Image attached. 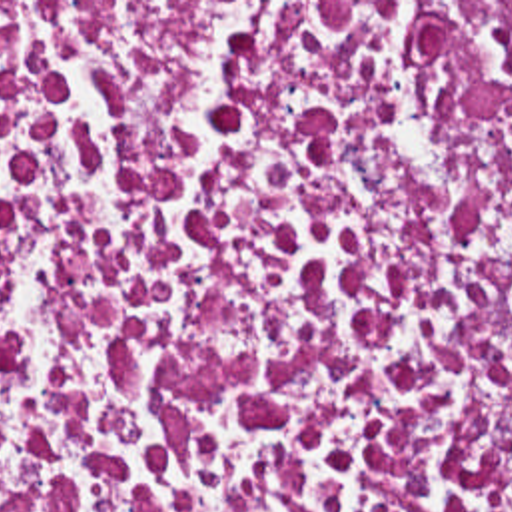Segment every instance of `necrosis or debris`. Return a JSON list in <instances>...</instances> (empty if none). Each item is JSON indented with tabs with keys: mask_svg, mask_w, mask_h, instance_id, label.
I'll use <instances>...</instances> for the list:
<instances>
[{
	"mask_svg": "<svg viewBox=\"0 0 512 512\" xmlns=\"http://www.w3.org/2000/svg\"><path fill=\"white\" fill-rule=\"evenodd\" d=\"M0 512H512V2H0Z\"/></svg>",
	"mask_w": 512,
	"mask_h": 512,
	"instance_id": "necrosis-or-debris-1",
	"label": "necrosis or debris"
}]
</instances>
